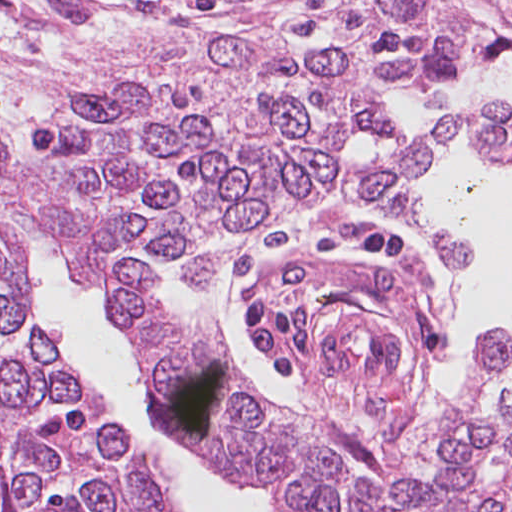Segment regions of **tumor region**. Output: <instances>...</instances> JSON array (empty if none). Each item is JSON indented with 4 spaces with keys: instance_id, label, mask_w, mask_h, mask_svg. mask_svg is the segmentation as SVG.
Instances as JSON below:
<instances>
[{
    "instance_id": "obj_1",
    "label": "tumor region",
    "mask_w": 512,
    "mask_h": 512,
    "mask_svg": "<svg viewBox=\"0 0 512 512\" xmlns=\"http://www.w3.org/2000/svg\"><path fill=\"white\" fill-rule=\"evenodd\" d=\"M314 48L182 15L138 20L31 104L0 110V512H77L172 481L39 302L16 244L47 242L148 367L153 425L203 472L312 435L234 365L196 309L234 255L339 193L465 258L409 193L468 127L512 165V105L460 110L393 152L378 92L512 59V0H266Z\"/></svg>"
}]
</instances>
